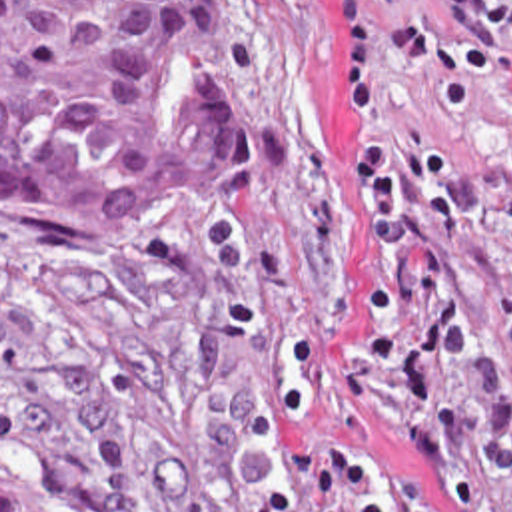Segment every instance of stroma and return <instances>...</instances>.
I'll use <instances>...</instances> for the list:
<instances>
[{
    "label": "stroma",
    "instance_id": "1",
    "mask_svg": "<svg viewBox=\"0 0 512 512\" xmlns=\"http://www.w3.org/2000/svg\"><path fill=\"white\" fill-rule=\"evenodd\" d=\"M262 167L164 251H102L0 217V452L70 512H336L322 436L437 510L431 470L352 406L360 213L336 115L334 0H244ZM473 191L453 378L463 512H512V87L457 135Z\"/></svg>",
    "mask_w": 512,
    "mask_h": 512
}]
</instances>
